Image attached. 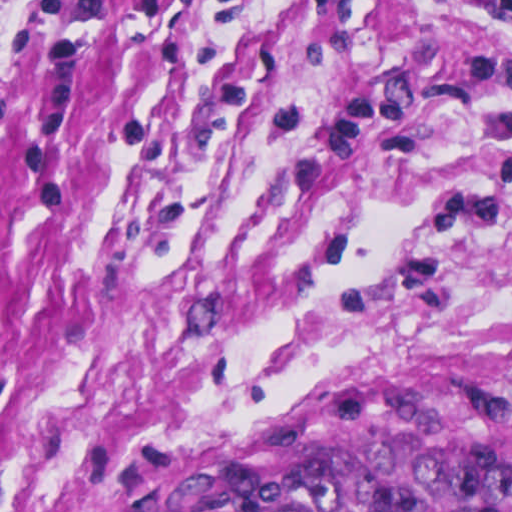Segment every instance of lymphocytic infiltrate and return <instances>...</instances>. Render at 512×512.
<instances>
[{"instance_id":"obj_1","label":"lymphocytic infiltrate","mask_w":512,"mask_h":512,"mask_svg":"<svg viewBox=\"0 0 512 512\" xmlns=\"http://www.w3.org/2000/svg\"><path fill=\"white\" fill-rule=\"evenodd\" d=\"M441 9L477 21L512 18V0H429Z\"/></svg>"}]
</instances>
